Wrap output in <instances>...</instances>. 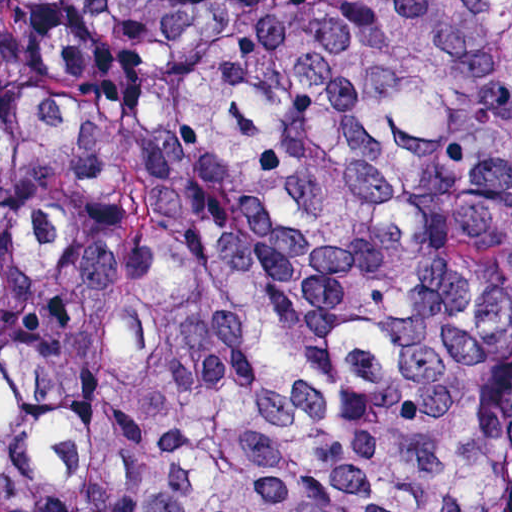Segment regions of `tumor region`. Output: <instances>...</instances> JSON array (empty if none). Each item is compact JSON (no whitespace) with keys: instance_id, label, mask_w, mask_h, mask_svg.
Wrapping results in <instances>:
<instances>
[{"instance_id":"e687c5a6","label":"tumor region","mask_w":512,"mask_h":512,"mask_svg":"<svg viewBox=\"0 0 512 512\" xmlns=\"http://www.w3.org/2000/svg\"><path fill=\"white\" fill-rule=\"evenodd\" d=\"M0 512H512V0H0Z\"/></svg>"}]
</instances>
